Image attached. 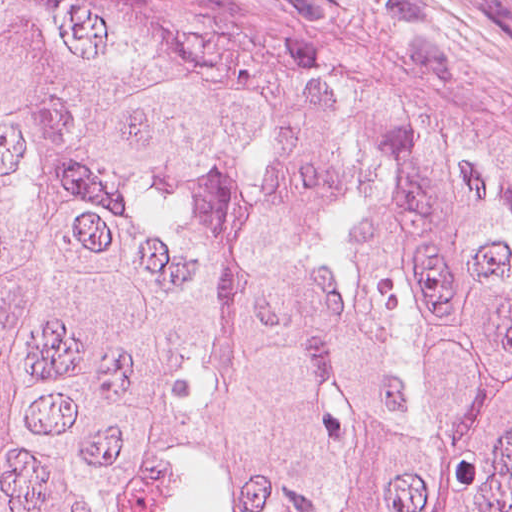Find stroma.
<instances>
[{
	"instance_id": "obj_1",
	"label": "stroma",
	"mask_w": 512,
	"mask_h": 512,
	"mask_svg": "<svg viewBox=\"0 0 512 512\" xmlns=\"http://www.w3.org/2000/svg\"><path fill=\"white\" fill-rule=\"evenodd\" d=\"M322 79L447 97L512 134V0H17Z\"/></svg>"
}]
</instances>
